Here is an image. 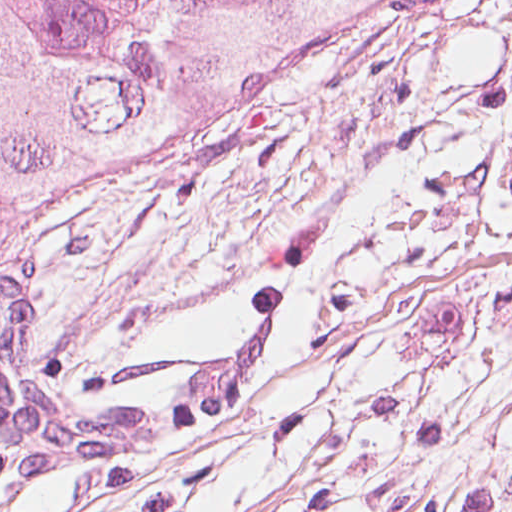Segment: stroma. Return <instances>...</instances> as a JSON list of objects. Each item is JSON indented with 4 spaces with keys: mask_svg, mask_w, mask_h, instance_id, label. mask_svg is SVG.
Segmentation results:
<instances>
[{
    "mask_svg": "<svg viewBox=\"0 0 512 512\" xmlns=\"http://www.w3.org/2000/svg\"><path fill=\"white\" fill-rule=\"evenodd\" d=\"M39 377L148 401L281 306L248 395L0 487L113 512H512V0H392L291 93L0 252Z\"/></svg>",
    "mask_w": 512,
    "mask_h": 512,
    "instance_id": "stroma-1",
    "label": "stroma"
}]
</instances>
